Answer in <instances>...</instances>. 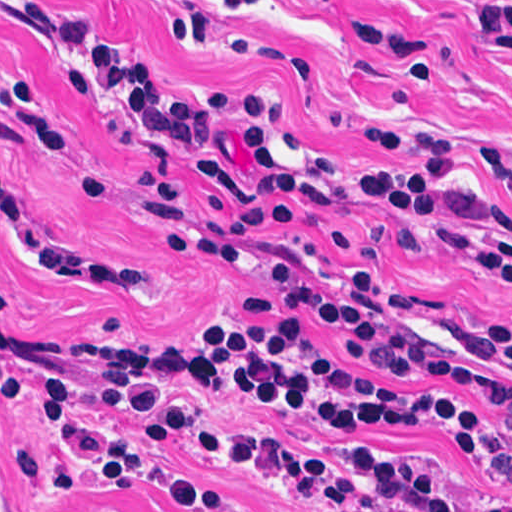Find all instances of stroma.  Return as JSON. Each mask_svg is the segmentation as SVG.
<instances>
[{
    "label": "stroma",
    "mask_w": 512,
    "mask_h": 512,
    "mask_svg": "<svg viewBox=\"0 0 512 512\" xmlns=\"http://www.w3.org/2000/svg\"><path fill=\"white\" fill-rule=\"evenodd\" d=\"M46 2L91 20L179 100L218 91L274 95L302 169L412 205L512 270V202L483 160V148L512 158V0ZM62 60L53 41L0 11V68L34 74L75 162L106 175L104 193L81 201L65 164L47 150L2 147L0 166L33 234L84 261L150 264L153 280L142 288H83L52 272L29 273L0 229V272L15 296L1 321L7 327L100 340L112 317L137 337L173 344L216 306L235 324H275L249 316L242 295L267 292L282 248L307 250L328 264L345 261L327 239L331 229L360 237L380 269L452 316L512 326V283L399 246L392 228L400 215L380 203L340 199L293 230L261 227L239 270L165 253L135 180L147 161L143 141L103 129L59 69ZM360 130L455 140L451 180L435 193L440 199L367 171L363 166L417 170L421 162L379 157ZM0 382L36 411L0 402V512H169L137 492L105 495L101 487L128 482L165 442L217 421L298 445L265 449L261 457L273 472L268 454L276 448L333 462L353 456L312 449L397 446L431 452L494 490L467 449L423 435L465 439L486 456L494 442L512 444V415L495 421L454 392L383 383L292 330L269 331L235 353L180 369L61 367L0 336ZM164 461L175 475L235 500L242 512H312L205 457L173 449ZM64 467L78 477L79 491L51 480ZM414 468L469 506H495L470 487Z\"/></svg>",
    "instance_id": "1"
}]
</instances>
